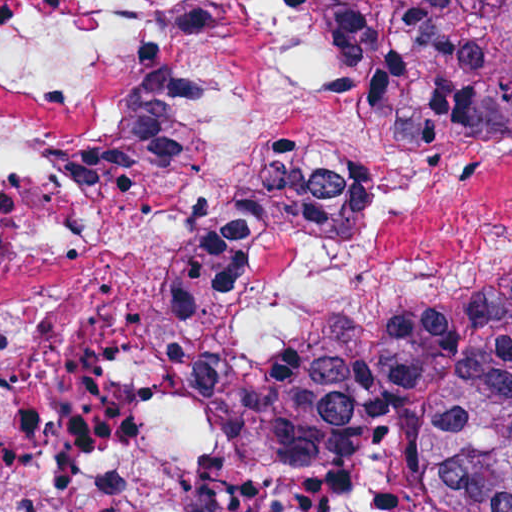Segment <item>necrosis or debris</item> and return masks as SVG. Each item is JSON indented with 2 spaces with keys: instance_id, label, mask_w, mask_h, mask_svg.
<instances>
[{
  "instance_id": "obj_1",
  "label": "necrosis or debris",
  "mask_w": 512,
  "mask_h": 512,
  "mask_svg": "<svg viewBox=\"0 0 512 512\" xmlns=\"http://www.w3.org/2000/svg\"><path fill=\"white\" fill-rule=\"evenodd\" d=\"M325 2L0 1V512H418L410 437L273 486L190 402L512 271V133L405 146Z\"/></svg>"
}]
</instances>
